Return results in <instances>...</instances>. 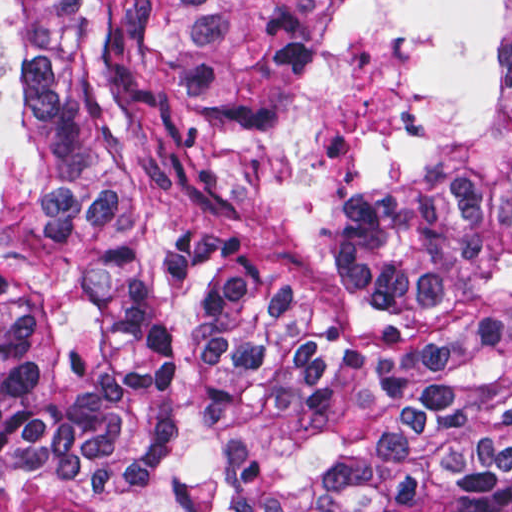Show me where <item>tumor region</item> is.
I'll return each mask as SVG.
<instances>
[{"label":"tumor region","instance_id":"obj_1","mask_svg":"<svg viewBox=\"0 0 512 512\" xmlns=\"http://www.w3.org/2000/svg\"><path fill=\"white\" fill-rule=\"evenodd\" d=\"M0 512H512V0H0Z\"/></svg>","mask_w":512,"mask_h":512}]
</instances>
